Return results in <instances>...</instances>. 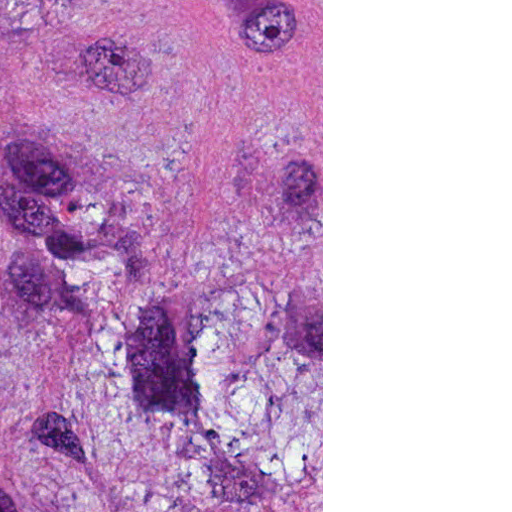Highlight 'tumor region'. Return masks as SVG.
Returning <instances> with one entry per match:
<instances>
[{"label":"tumor region","mask_w":512,"mask_h":512,"mask_svg":"<svg viewBox=\"0 0 512 512\" xmlns=\"http://www.w3.org/2000/svg\"><path fill=\"white\" fill-rule=\"evenodd\" d=\"M0 512H161V0H0Z\"/></svg>","instance_id":"tumor-region-1"}]
</instances>
